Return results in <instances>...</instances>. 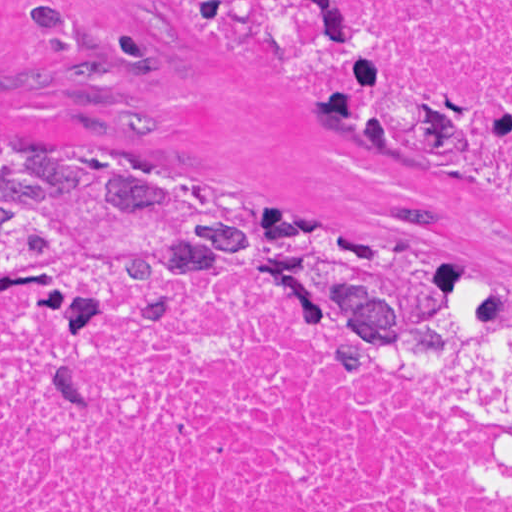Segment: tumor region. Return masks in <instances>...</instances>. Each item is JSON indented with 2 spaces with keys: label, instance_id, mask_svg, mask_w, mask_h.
Instances as JSON below:
<instances>
[{
  "label": "tumor region",
  "instance_id": "tumor-region-1",
  "mask_svg": "<svg viewBox=\"0 0 512 512\" xmlns=\"http://www.w3.org/2000/svg\"><path fill=\"white\" fill-rule=\"evenodd\" d=\"M331 94L325 124L392 158L463 154L478 108L454 89L402 84L341 0H179ZM141 255H288L448 288L511 311L495 283L367 237L191 205L41 146H0V285L43 264Z\"/></svg>",
  "mask_w": 512,
  "mask_h": 512
}]
</instances>
